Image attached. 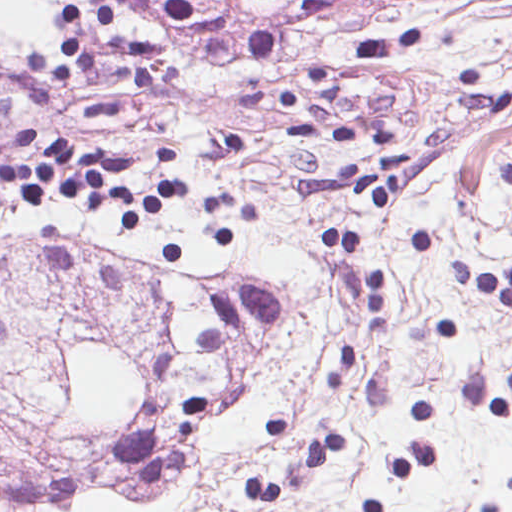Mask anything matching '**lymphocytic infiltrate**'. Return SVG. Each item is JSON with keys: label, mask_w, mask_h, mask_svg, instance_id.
<instances>
[{"label": "lymphocytic infiltrate", "mask_w": 512, "mask_h": 512, "mask_svg": "<svg viewBox=\"0 0 512 512\" xmlns=\"http://www.w3.org/2000/svg\"><path fill=\"white\" fill-rule=\"evenodd\" d=\"M339 0H304L303 6L324 17ZM317 95L306 115L288 129L299 138L338 145H379L386 153L371 167L338 164L332 180L302 184L306 194H351L385 207L404 208L406 158L396 153L385 136L362 128H327L337 79L320 65L312 71ZM175 151L155 146L149 156L157 173L149 192H135L125 176L131 158H118L79 148L19 124L0 138V181L16 199L37 208L51 192L61 191L76 206H114L123 234H140L152 219L176 202V177L170 164ZM2 197L0 195V206ZM332 253L346 251L363 281V319L381 325L388 278L362 253V239L341 228L318 230L309 241ZM453 282L501 306L512 321V265L483 271L468 261H453Z\"/></svg>", "instance_id": "1"}]
</instances>
